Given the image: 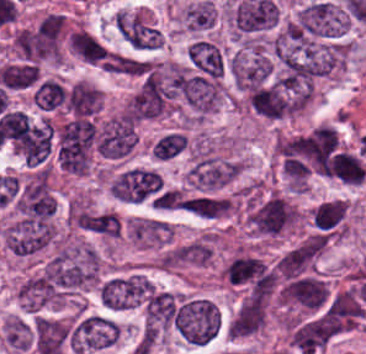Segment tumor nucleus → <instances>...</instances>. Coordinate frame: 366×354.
Instances as JSON below:
<instances>
[{
  "mask_svg": "<svg viewBox=\"0 0 366 354\" xmlns=\"http://www.w3.org/2000/svg\"><path fill=\"white\" fill-rule=\"evenodd\" d=\"M105 187L117 201L164 204V183L153 166L125 164L108 175Z\"/></svg>",
  "mask_w": 366,
  "mask_h": 354,
  "instance_id": "1",
  "label": "tumor nucleus"
},
{
  "mask_svg": "<svg viewBox=\"0 0 366 354\" xmlns=\"http://www.w3.org/2000/svg\"><path fill=\"white\" fill-rule=\"evenodd\" d=\"M184 302L179 293L152 287L141 306L140 338L144 345L156 343L175 327Z\"/></svg>",
  "mask_w": 366,
  "mask_h": 354,
  "instance_id": "2",
  "label": "tumor nucleus"
},
{
  "mask_svg": "<svg viewBox=\"0 0 366 354\" xmlns=\"http://www.w3.org/2000/svg\"><path fill=\"white\" fill-rule=\"evenodd\" d=\"M120 334V324L110 315L78 309L68 339L73 350L88 354L114 346Z\"/></svg>",
  "mask_w": 366,
  "mask_h": 354,
  "instance_id": "3",
  "label": "tumor nucleus"
},
{
  "mask_svg": "<svg viewBox=\"0 0 366 354\" xmlns=\"http://www.w3.org/2000/svg\"><path fill=\"white\" fill-rule=\"evenodd\" d=\"M242 160L209 149L196 148L188 169L187 183L192 190L216 191L240 172Z\"/></svg>",
  "mask_w": 366,
  "mask_h": 354,
  "instance_id": "4",
  "label": "tumor nucleus"
},
{
  "mask_svg": "<svg viewBox=\"0 0 366 354\" xmlns=\"http://www.w3.org/2000/svg\"><path fill=\"white\" fill-rule=\"evenodd\" d=\"M176 326L186 343L204 344L221 327V313L216 303L197 296H183L176 316Z\"/></svg>",
  "mask_w": 366,
  "mask_h": 354,
  "instance_id": "5",
  "label": "tumor nucleus"
},
{
  "mask_svg": "<svg viewBox=\"0 0 366 354\" xmlns=\"http://www.w3.org/2000/svg\"><path fill=\"white\" fill-rule=\"evenodd\" d=\"M348 26L329 0L308 2L293 19L296 37L336 38L346 33Z\"/></svg>",
  "mask_w": 366,
  "mask_h": 354,
  "instance_id": "6",
  "label": "tumor nucleus"
},
{
  "mask_svg": "<svg viewBox=\"0 0 366 354\" xmlns=\"http://www.w3.org/2000/svg\"><path fill=\"white\" fill-rule=\"evenodd\" d=\"M113 21L118 33L131 48L155 49L162 41V32L139 10L119 8Z\"/></svg>",
  "mask_w": 366,
  "mask_h": 354,
  "instance_id": "7",
  "label": "tumor nucleus"
},
{
  "mask_svg": "<svg viewBox=\"0 0 366 354\" xmlns=\"http://www.w3.org/2000/svg\"><path fill=\"white\" fill-rule=\"evenodd\" d=\"M350 203L341 198H328L311 211L313 229L330 239H338L347 231Z\"/></svg>",
  "mask_w": 366,
  "mask_h": 354,
  "instance_id": "8",
  "label": "tumor nucleus"
},
{
  "mask_svg": "<svg viewBox=\"0 0 366 354\" xmlns=\"http://www.w3.org/2000/svg\"><path fill=\"white\" fill-rule=\"evenodd\" d=\"M264 275L262 256L239 250L224 263L223 277L238 286L253 287Z\"/></svg>",
  "mask_w": 366,
  "mask_h": 354,
  "instance_id": "9",
  "label": "tumor nucleus"
},
{
  "mask_svg": "<svg viewBox=\"0 0 366 354\" xmlns=\"http://www.w3.org/2000/svg\"><path fill=\"white\" fill-rule=\"evenodd\" d=\"M180 206L183 211L204 218L226 217L234 211L230 196L209 191H196L182 196Z\"/></svg>",
  "mask_w": 366,
  "mask_h": 354,
  "instance_id": "10",
  "label": "tumor nucleus"
},
{
  "mask_svg": "<svg viewBox=\"0 0 366 354\" xmlns=\"http://www.w3.org/2000/svg\"><path fill=\"white\" fill-rule=\"evenodd\" d=\"M175 260L181 264L206 265L213 260V246L210 237L199 235L176 245Z\"/></svg>",
  "mask_w": 366,
  "mask_h": 354,
  "instance_id": "11",
  "label": "tumor nucleus"
},
{
  "mask_svg": "<svg viewBox=\"0 0 366 354\" xmlns=\"http://www.w3.org/2000/svg\"><path fill=\"white\" fill-rule=\"evenodd\" d=\"M183 28L200 32L215 24V6L204 0L191 2L181 13Z\"/></svg>",
  "mask_w": 366,
  "mask_h": 354,
  "instance_id": "12",
  "label": "tumor nucleus"
},
{
  "mask_svg": "<svg viewBox=\"0 0 366 354\" xmlns=\"http://www.w3.org/2000/svg\"><path fill=\"white\" fill-rule=\"evenodd\" d=\"M65 96V87L53 77H46L33 93V98L44 108L65 102Z\"/></svg>",
  "mask_w": 366,
  "mask_h": 354,
  "instance_id": "13",
  "label": "tumor nucleus"
}]
</instances>
